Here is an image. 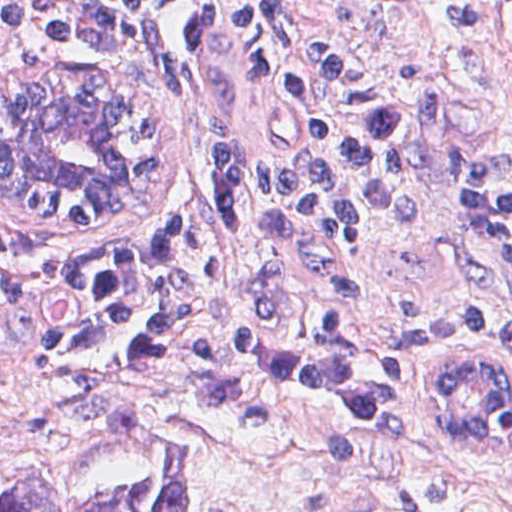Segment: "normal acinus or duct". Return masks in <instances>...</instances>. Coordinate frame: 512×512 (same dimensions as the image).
<instances>
[{
  "label": "normal acinus or duct",
  "mask_w": 512,
  "mask_h": 512,
  "mask_svg": "<svg viewBox=\"0 0 512 512\" xmlns=\"http://www.w3.org/2000/svg\"><path fill=\"white\" fill-rule=\"evenodd\" d=\"M83 84L34 67L5 90L0 183L61 211L105 216L122 181L126 138L107 102ZM490 348L423 365L426 410L464 446L482 447L512 397V363Z\"/></svg>",
  "instance_id": "obj_1"
}]
</instances>
